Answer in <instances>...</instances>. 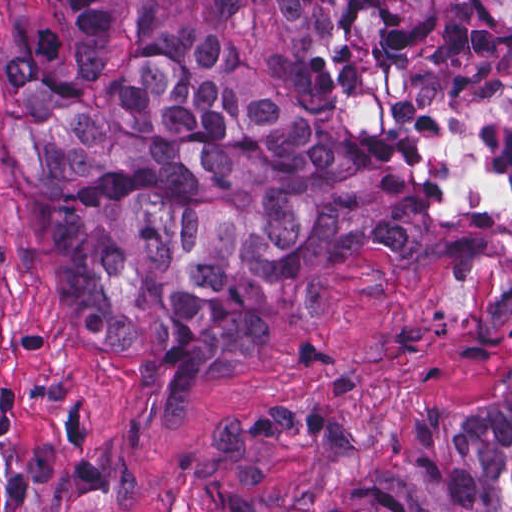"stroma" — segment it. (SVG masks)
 Instances as JSON below:
<instances>
[{
	"label": "stroma",
	"mask_w": 512,
	"mask_h": 512,
	"mask_svg": "<svg viewBox=\"0 0 512 512\" xmlns=\"http://www.w3.org/2000/svg\"><path fill=\"white\" fill-rule=\"evenodd\" d=\"M24 1H126L136 28L207 34L261 83L334 109L356 139L425 144L476 236L261 296L238 362L204 397L172 398L76 328L0 126V512H215L229 486L326 497L356 484L414 410L512 395V104L462 61L410 59L378 21L309 32L231 2L512 0H0V39Z\"/></svg>",
	"instance_id": "stroma-1"
}]
</instances>
